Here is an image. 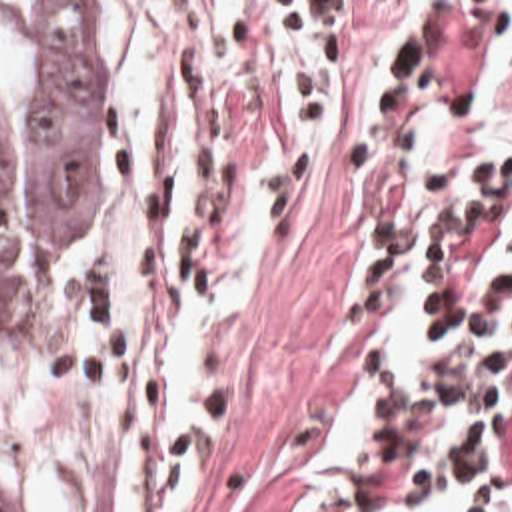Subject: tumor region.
I'll return each instance as SVG.
<instances>
[{"label": "tumor region", "instance_id": "obj_1", "mask_svg": "<svg viewBox=\"0 0 512 512\" xmlns=\"http://www.w3.org/2000/svg\"><path fill=\"white\" fill-rule=\"evenodd\" d=\"M120 148L98 2H0V341L49 329L60 262L102 218Z\"/></svg>", "mask_w": 512, "mask_h": 512}]
</instances>
